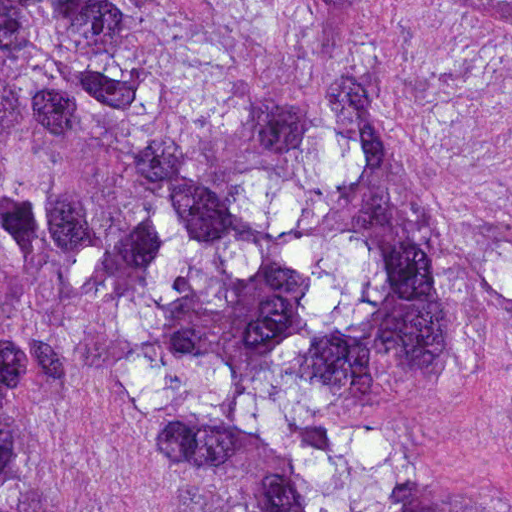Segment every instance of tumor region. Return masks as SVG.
Returning <instances> with one entry per match:
<instances>
[{
  "instance_id": "tumor-region-1",
  "label": "tumor region",
  "mask_w": 512,
  "mask_h": 512,
  "mask_svg": "<svg viewBox=\"0 0 512 512\" xmlns=\"http://www.w3.org/2000/svg\"><path fill=\"white\" fill-rule=\"evenodd\" d=\"M0 512H512V0H0Z\"/></svg>"
}]
</instances>
